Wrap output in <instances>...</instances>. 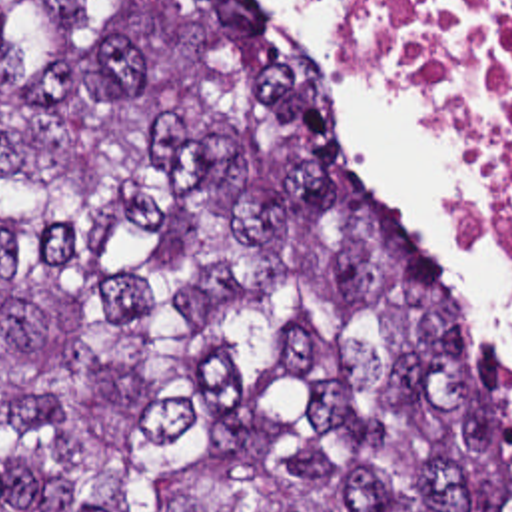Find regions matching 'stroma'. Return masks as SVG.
Returning <instances> with one entry per match:
<instances>
[{"label": "stroma", "mask_w": 512, "mask_h": 512, "mask_svg": "<svg viewBox=\"0 0 512 512\" xmlns=\"http://www.w3.org/2000/svg\"><path fill=\"white\" fill-rule=\"evenodd\" d=\"M412 99H414V97H412ZM414 101H416V99H414ZM416 103L422 107V103H420V101H416ZM422 109H424V107H422ZM339 147H341V155H343V159H345V165H347L349 173L353 175V179L359 183V187H361V189H363V191H365V193H367V195H369V197H371V199H373V201H375V203H377V205H379V207H381V209H383V211H385V213H387V215H389V217L395 221V223H399L402 229H406V227L402 225L401 221H399L397 213H395V211L391 209V205L387 203V199L383 197V193H381V191H379V189H377V187H375L371 181H367V179L361 175V171H359L357 167H353V165L349 163V159H347V153H345V149H343L341 141H339ZM406 231H408V229H406ZM408 233H410V231H408ZM410 235H412V233H410ZM412 239H414V237H412ZM468 241H470V239H468ZM504 243H510V245H512V229H506V231L498 233V235H496V239L490 243V247H488V249H486V247H482V245H478V243H474V241H470V245H472V247H476V249H480V251H484V253L500 251Z\"/></svg>", "instance_id": "35a3bbf8"}]
</instances>
